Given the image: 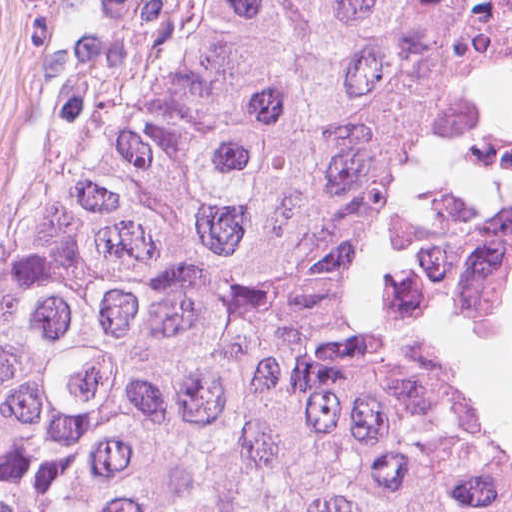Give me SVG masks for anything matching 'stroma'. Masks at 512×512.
<instances>
[{
  "label": "stroma",
  "instance_id": "35a3bbf8",
  "mask_svg": "<svg viewBox=\"0 0 512 512\" xmlns=\"http://www.w3.org/2000/svg\"><path fill=\"white\" fill-rule=\"evenodd\" d=\"M136 0H0V300L34 189L90 114Z\"/></svg>",
  "mask_w": 512,
  "mask_h": 512
}]
</instances>
